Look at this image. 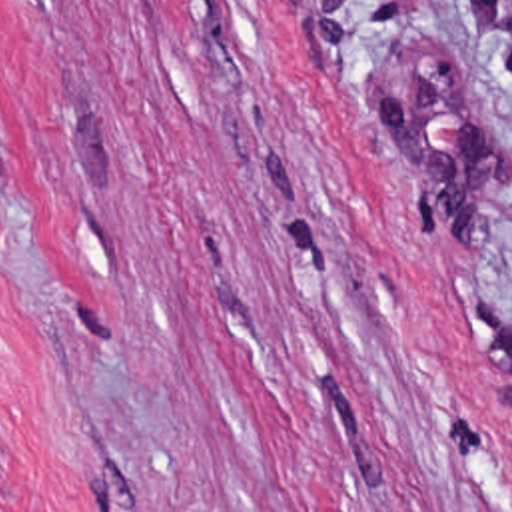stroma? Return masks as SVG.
I'll list each match as a JSON object with an SVG mask.
<instances>
[{
    "label": "stroma",
    "instance_id": "35a3bbf8",
    "mask_svg": "<svg viewBox=\"0 0 512 512\" xmlns=\"http://www.w3.org/2000/svg\"><path fill=\"white\" fill-rule=\"evenodd\" d=\"M0 512H512V0H0Z\"/></svg>",
    "mask_w": 512,
    "mask_h": 512
}]
</instances>
